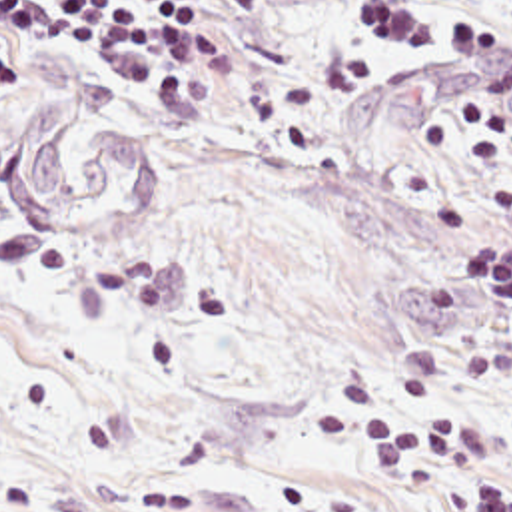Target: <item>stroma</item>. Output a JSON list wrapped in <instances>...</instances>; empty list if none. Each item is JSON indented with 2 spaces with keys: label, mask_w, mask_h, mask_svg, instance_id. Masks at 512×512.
Listing matches in <instances>:
<instances>
[{
  "label": "stroma",
  "mask_w": 512,
  "mask_h": 512,
  "mask_svg": "<svg viewBox=\"0 0 512 512\" xmlns=\"http://www.w3.org/2000/svg\"><path fill=\"white\" fill-rule=\"evenodd\" d=\"M512 53V7L469 0ZM387 15L409 31V43ZM423 0H262L214 75L152 85L92 59L0 83V133L68 91L60 149L148 137L164 183L86 227H24L0 197V504L26 512H455L473 488L383 478L337 386L413 422L467 416L512 486V312L451 263L512 243V115L431 69Z\"/></svg>",
  "instance_id": "1"
}]
</instances>
